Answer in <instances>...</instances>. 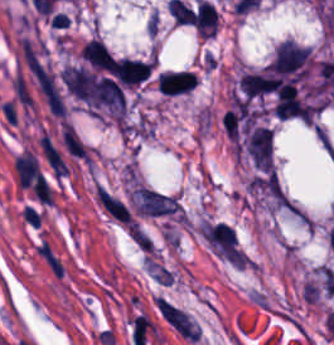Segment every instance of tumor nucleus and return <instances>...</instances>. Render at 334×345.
Segmentation results:
<instances>
[{
	"mask_svg": "<svg viewBox=\"0 0 334 345\" xmlns=\"http://www.w3.org/2000/svg\"><path fill=\"white\" fill-rule=\"evenodd\" d=\"M245 152L259 171H273V130L268 125H248L245 133Z\"/></svg>",
	"mask_w": 334,
	"mask_h": 345,
	"instance_id": "2f306a5c",
	"label": "tumor nucleus"
},
{
	"mask_svg": "<svg viewBox=\"0 0 334 345\" xmlns=\"http://www.w3.org/2000/svg\"><path fill=\"white\" fill-rule=\"evenodd\" d=\"M153 62L139 61L127 58L113 60L108 71L121 86H135L146 78Z\"/></svg>",
	"mask_w": 334,
	"mask_h": 345,
	"instance_id": "8643909e",
	"label": "tumor nucleus"
},
{
	"mask_svg": "<svg viewBox=\"0 0 334 345\" xmlns=\"http://www.w3.org/2000/svg\"><path fill=\"white\" fill-rule=\"evenodd\" d=\"M197 85V77L189 71L164 72L158 77L159 94H186Z\"/></svg>",
	"mask_w": 334,
	"mask_h": 345,
	"instance_id": "5ab6c2c4",
	"label": "tumor nucleus"
},
{
	"mask_svg": "<svg viewBox=\"0 0 334 345\" xmlns=\"http://www.w3.org/2000/svg\"><path fill=\"white\" fill-rule=\"evenodd\" d=\"M218 12L214 5L206 0H198L195 26L198 34L213 37L217 28Z\"/></svg>",
	"mask_w": 334,
	"mask_h": 345,
	"instance_id": "2cbd58db",
	"label": "tumor nucleus"
}]
</instances>
